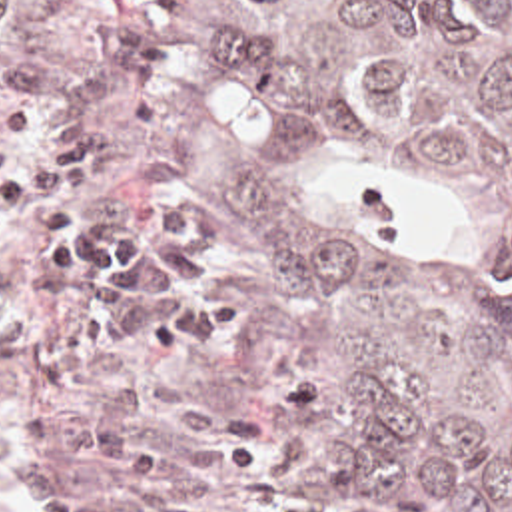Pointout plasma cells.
<instances>
[{
  "label": "plasma cells",
  "mask_w": 512,
  "mask_h": 512,
  "mask_svg": "<svg viewBox=\"0 0 512 512\" xmlns=\"http://www.w3.org/2000/svg\"><path fill=\"white\" fill-rule=\"evenodd\" d=\"M156 69L137 16H107L75 51L49 22L1 89L0 367L75 397L95 465L91 489L51 493L37 512H218L216 491L264 463L244 409L218 395L186 399L137 451L145 391L89 375L208 345L242 313L200 215L158 197L91 203L97 171L149 133L143 97L105 139Z\"/></svg>",
  "instance_id": "9512152a"
}]
</instances>
